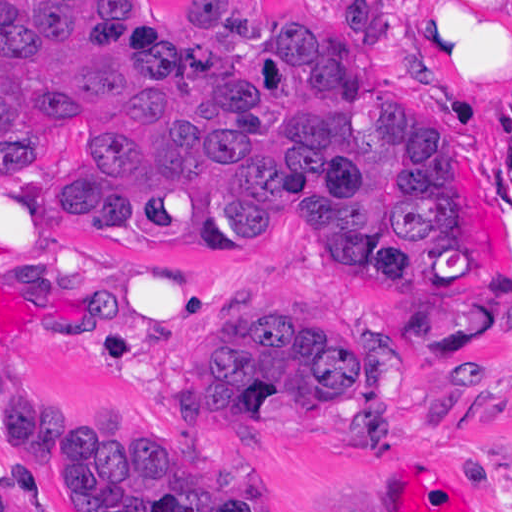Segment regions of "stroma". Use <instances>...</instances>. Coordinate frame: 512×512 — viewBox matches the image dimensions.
I'll return each instance as SVG.
<instances>
[{
	"label": "stroma",
	"mask_w": 512,
	"mask_h": 512,
	"mask_svg": "<svg viewBox=\"0 0 512 512\" xmlns=\"http://www.w3.org/2000/svg\"><path fill=\"white\" fill-rule=\"evenodd\" d=\"M9 0H0V6ZM246 0H179L210 41ZM368 53L399 77V131L425 191L474 263V298L401 306L260 247L151 264L42 225L20 175L0 172V387L169 454L213 482H260L265 512H512V0H340ZM241 314H270L346 346L397 341L406 389L384 456L198 409L197 359ZM41 512H71L0 433Z\"/></svg>",
	"instance_id": "1"
}]
</instances>
